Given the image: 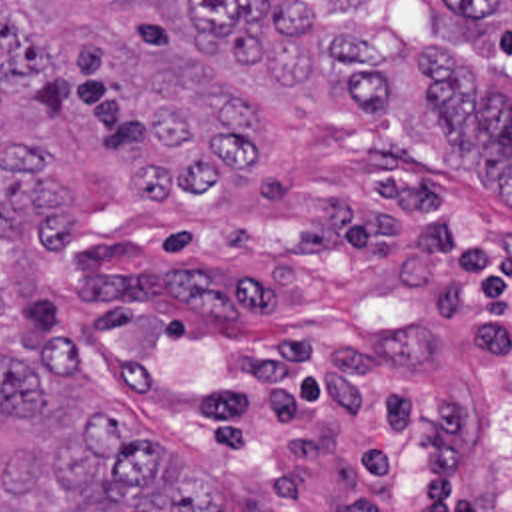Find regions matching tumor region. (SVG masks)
Returning <instances> with one entry per match:
<instances>
[{
	"instance_id": "tumor-region-1",
	"label": "tumor region",
	"mask_w": 512,
	"mask_h": 512,
	"mask_svg": "<svg viewBox=\"0 0 512 512\" xmlns=\"http://www.w3.org/2000/svg\"><path fill=\"white\" fill-rule=\"evenodd\" d=\"M512 2H0V94L89 112L145 192L204 194L262 152L260 112L430 118L512 208ZM13 244H71L65 188L0 144L1 270ZM0 512H222L147 423L93 403L61 335L0 343Z\"/></svg>"
}]
</instances>
